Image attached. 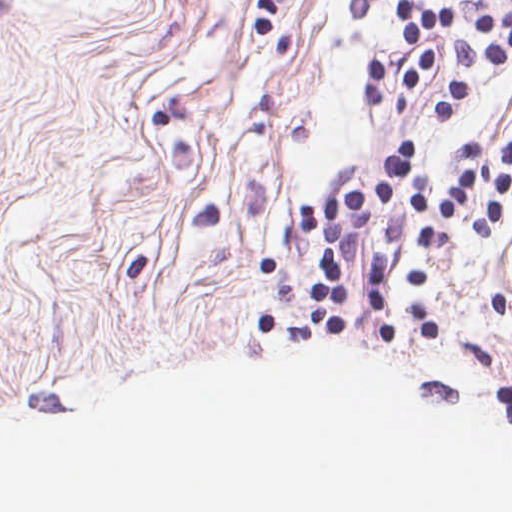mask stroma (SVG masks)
Returning <instances> with one entry per match:
<instances>
[{"mask_svg":"<svg viewBox=\"0 0 512 512\" xmlns=\"http://www.w3.org/2000/svg\"><path fill=\"white\" fill-rule=\"evenodd\" d=\"M394 0H0V174L311 275L326 242L296 230L306 202L380 182L396 140L434 194L451 146L486 158L512 133V55L474 61L452 118L433 114L457 61L392 118L405 61ZM458 12L462 32L512 0H410ZM389 299L512 340V195L488 236L449 217L427 246L408 201ZM343 285L368 293L365 249Z\"/></svg>","mask_w":512,"mask_h":512,"instance_id":"1","label":"stroma"}]
</instances>
